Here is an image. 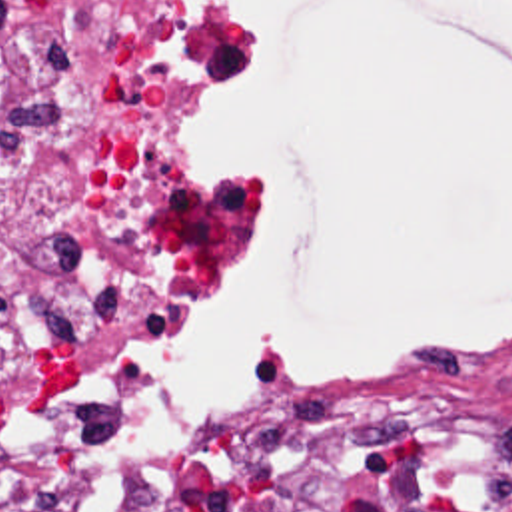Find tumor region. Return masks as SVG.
Returning <instances> with one entry per match:
<instances>
[{
	"instance_id": "e687c5a6",
	"label": "tumor region",
	"mask_w": 512,
	"mask_h": 512,
	"mask_svg": "<svg viewBox=\"0 0 512 512\" xmlns=\"http://www.w3.org/2000/svg\"><path fill=\"white\" fill-rule=\"evenodd\" d=\"M159 501V481L131 471L121 485L115 512H155Z\"/></svg>"
}]
</instances>
